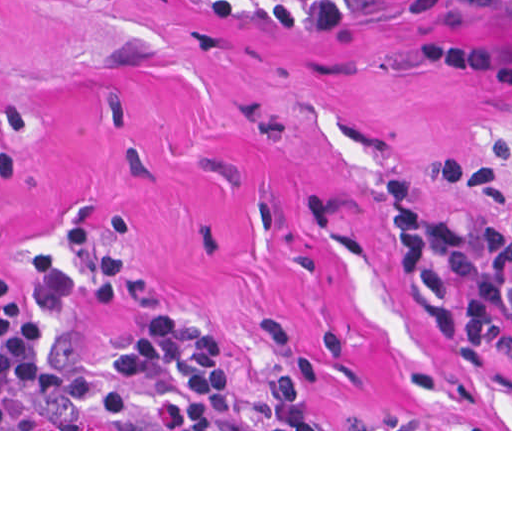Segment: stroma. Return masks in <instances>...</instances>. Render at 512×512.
<instances>
[{
    "label": "stroma",
    "instance_id": "obj_1",
    "mask_svg": "<svg viewBox=\"0 0 512 512\" xmlns=\"http://www.w3.org/2000/svg\"><path fill=\"white\" fill-rule=\"evenodd\" d=\"M0 274L42 351L207 321L243 395L339 429L512 431L403 283L388 184L512 215V0H388L272 31L207 0H0Z\"/></svg>",
    "mask_w": 512,
    "mask_h": 512
}]
</instances>
